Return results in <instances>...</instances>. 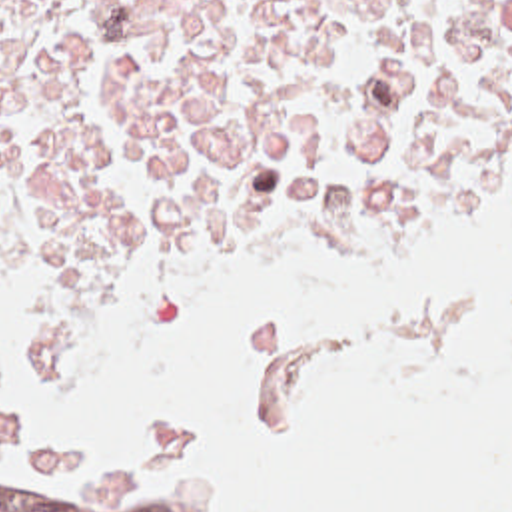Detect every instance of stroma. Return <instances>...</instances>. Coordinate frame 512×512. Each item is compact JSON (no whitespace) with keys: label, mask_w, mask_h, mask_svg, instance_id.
<instances>
[{"label":"stroma","mask_w":512,"mask_h":512,"mask_svg":"<svg viewBox=\"0 0 512 512\" xmlns=\"http://www.w3.org/2000/svg\"><path fill=\"white\" fill-rule=\"evenodd\" d=\"M510 182H512V160L502 166V170L492 178V182L482 190V194L472 202V206H470L466 212H462V214H458V216H454V218H450V220L438 224L436 228L428 230L426 234H422L420 238L412 240L410 244H406V246H402V248H398V250H394V252L382 256V258H376V260H372V262H368V264H364V266H360V268H356V270H352V272L328 274V276H285V278H291V280H297V282H305V284H342V282L352 280V278H356V276H362V274H366L368 270H372V268H376V266H382V264H386V262H390V260H394V258H398V256L410 254V252L420 250V248H424V246H428L426 250H430V248H432L434 244H438L454 226H458L460 222H464V220H466L468 216H472L474 212L482 210V208H484L504 186H508ZM257 236H259V230H257V232H249V234H241V236L227 238L223 244H219V246H217L211 254H207L203 260H199V262H195L193 266L181 270L177 276H173L167 284L161 286V290H159V294H157V300H155L153 308H151L147 314H151V312H155V310L167 306L171 300H175V298L183 292V288L189 284V280H191L193 276L201 274L203 270H207V268H211V266H217V264H247V266H255V268H257V262H255ZM147 314H145V316H147ZM145 316H143V318H145ZM107 338H109V336H93V334H89V332L61 328L59 324L53 322V346H51V348H55V346H59V344H95V342H103V340H107ZM77 462H87V460H63V462H55V464L49 466L47 470H33V476H31L29 480H33V478H37V476H41V474H45V472H49V470H53V468H57V466L77 464ZM111 464L123 468L125 472L133 474L135 478H139V480H143V482H151V480H147V478L143 476L141 468L135 466V464H131V462H111ZM29 480H27V482H29ZM153 484H155V482H153ZM197 498H199V496H197ZM201 500H203V498H201ZM205 502H207V500H205ZM231 512H237V510H231Z\"/></svg>","instance_id":"1"}]
</instances>
